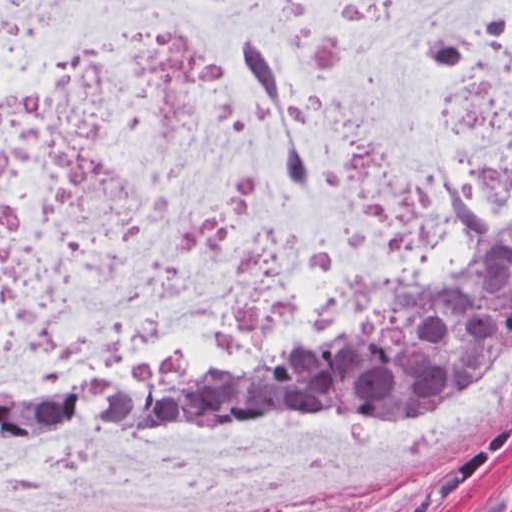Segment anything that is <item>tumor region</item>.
<instances>
[{"label":"tumor region","mask_w":512,"mask_h":512,"mask_svg":"<svg viewBox=\"0 0 512 512\" xmlns=\"http://www.w3.org/2000/svg\"><path fill=\"white\" fill-rule=\"evenodd\" d=\"M511 336L512 246L428 301L367 316L298 351L213 371L0 394V431L133 433L218 403L394 414L484 368Z\"/></svg>","instance_id":"e687c5a6"}]
</instances>
